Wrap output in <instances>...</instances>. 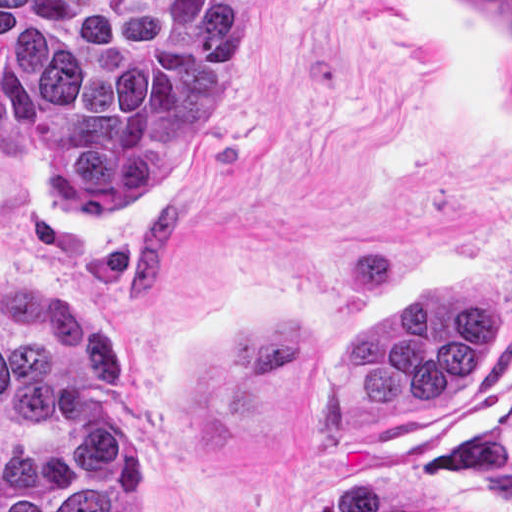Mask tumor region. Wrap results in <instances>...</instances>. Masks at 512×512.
I'll list each match as a JSON object with an SVG mask.
<instances>
[{"instance_id":"1","label":"tumor region","mask_w":512,"mask_h":512,"mask_svg":"<svg viewBox=\"0 0 512 512\" xmlns=\"http://www.w3.org/2000/svg\"><path fill=\"white\" fill-rule=\"evenodd\" d=\"M512 38V1H474ZM260 1H0V128L72 219H129L178 183L213 128ZM502 333L501 283L421 289L335 362L366 412L459 404ZM130 389L124 323L0 274V512H146L149 440L114 411ZM311 512H430L404 481H348Z\"/></svg>"}]
</instances>
